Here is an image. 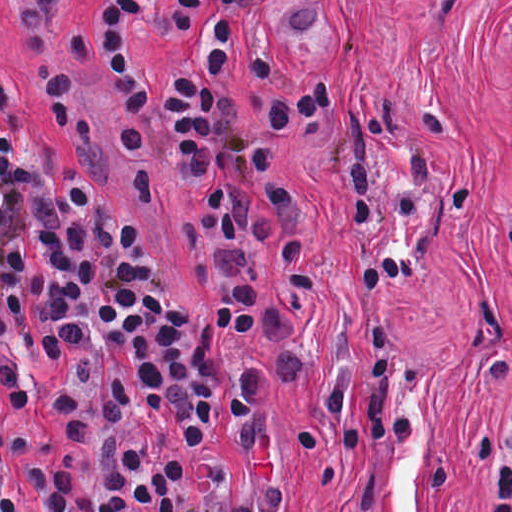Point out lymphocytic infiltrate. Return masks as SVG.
<instances>
[{
  "mask_svg": "<svg viewBox=\"0 0 512 512\" xmlns=\"http://www.w3.org/2000/svg\"><path fill=\"white\" fill-rule=\"evenodd\" d=\"M451 10L458 0H432ZM326 0L291 13L307 29ZM258 0H101L111 77L145 194L195 167L219 183L210 210L221 299L234 350L176 289L133 215L105 199L81 163L90 116L60 48L50 0H19L26 58L51 106L60 147L42 145L0 73V374L24 408L57 404L68 452L41 462L43 512H289V477L261 398L287 389L304 356L262 267L273 242L295 287L316 291L325 222L277 150L322 117L341 89L324 78L253 108L227 86L279 71L245 41ZM457 110L427 101L405 132L386 189L362 134L329 172L345 206L351 286L386 293L415 274L435 223L467 206V188L415 137L445 142ZM370 412L348 419L346 374L325 399L329 434L399 465L409 412L386 340ZM483 512H512V397L475 434ZM0 512H18L17 476L0 427Z\"/></svg>",
  "mask_w": 512,
  "mask_h": 512,
  "instance_id": "f902f5d3",
  "label": "lymphocytic infiltrate"
}]
</instances>
